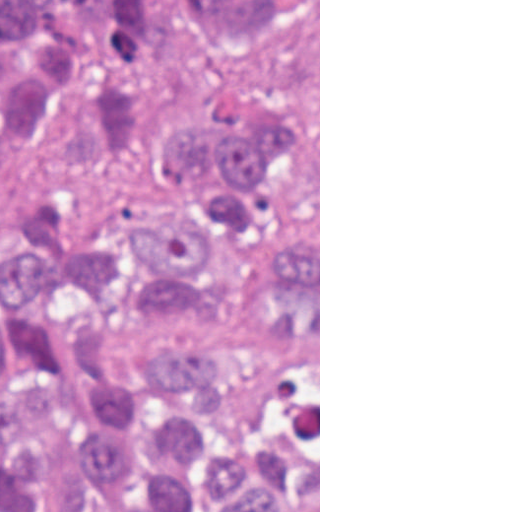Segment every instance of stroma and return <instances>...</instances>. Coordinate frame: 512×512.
<instances>
[{
  "label": "stroma",
  "mask_w": 512,
  "mask_h": 512,
  "mask_svg": "<svg viewBox=\"0 0 512 512\" xmlns=\"http://www.w3.org/2000/svg\"><path fill=\"white\" fill-rule=\"evenodd\" d=\"M102 136L81 108L61 115L25 155L0 170V232ZM319 512H320V0H319Z\"/></svg>",
  "instance_id": "obj_1"
}]
</instances>
